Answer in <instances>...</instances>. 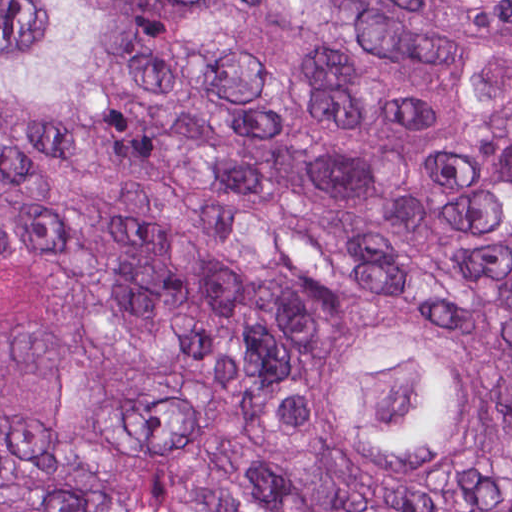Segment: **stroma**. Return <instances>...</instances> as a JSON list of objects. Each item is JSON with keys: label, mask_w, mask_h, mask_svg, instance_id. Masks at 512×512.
<instances>
[{"label": "stroma", "mask_w": 512, "mask_h": 512, "mask_svg": "<svg viewBox=\"0 0 512 512\" xmlns=\"http://www.w3.org/2000/svg\"><path fill=\"white\" fill-rule=\"evenodd\" d=\"M119 67L113 100L36 105L0 89V118L75 141L120 139L139 88L137 41L92 0ZM454 45L512 126V86L494 48L446 0H360ZM512 307L449 328L353 308L302 317L277 355V395L301 452L350 486L445 493L503 448L511 398L489 348ZM81 340V263L70 242L0 245V406H41L67 387Z\"/></svg>", "instance_id": "35a3bbf8"}]
</instances>
